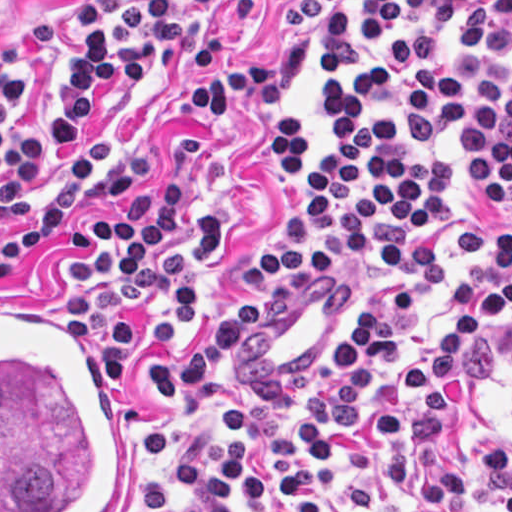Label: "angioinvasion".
<instances>
[{"instance_id":"1","label":"angioinvasion","mask_w":512,"mask_h":512,"mask_svg":"<svg viewBox=\"0 0 512 512\" xmlns=\"http://www.w3.org/2000/svg\"><path fill=\"white\" fill-rule=\"evenodd\" d=\"M0 301V512H129L131 435L73 319Z\"/></svg>"}]
</instances>
